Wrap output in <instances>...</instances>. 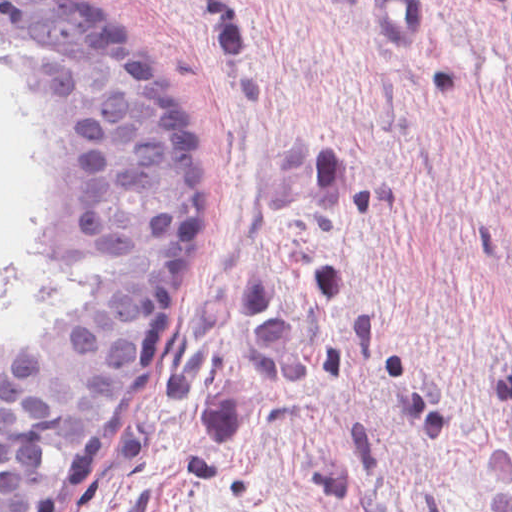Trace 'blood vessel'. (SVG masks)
Instances as JSON below:
<instances>
[{
    "label": "blood vessel",
    "instance_id": "8fb6f2fc",
    "mask_svg": "<svg viewBox=\"0 0 512 512\" xmlns=\"http://www.w3.org/2000/svg\"><path fill=\"white\" fill-rule=\"evenodd\" d=\"M364 18L374 31L397 41L419 40L425 31L422 0H365Z\"/></svg>",
    "mask_w": 512,
    "mask_h": 512
}]
</instances>
